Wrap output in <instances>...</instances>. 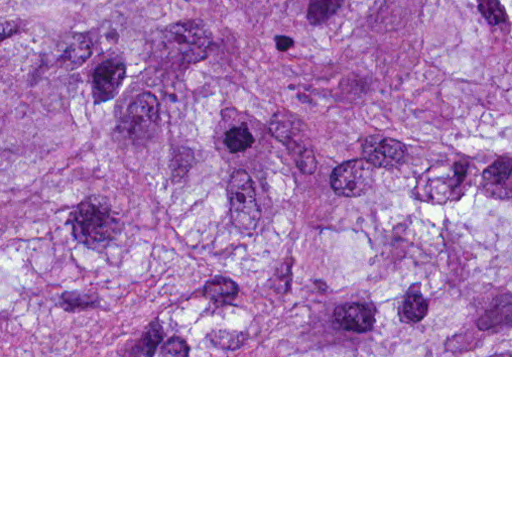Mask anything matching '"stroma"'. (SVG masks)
<instances>
[{
  "label": "stroma",
  "instance_id": "stroma-1",
  "mask_svg": "<svg viewBox=\"0 0 512 512\" xmlns=\"http://www.w3.org/2000/svg\"><path fill=\"white\" fill-rule=\"evenodd\" d=\"M0 357H512V356H0Z\"/></svg>",
  "mask_w": 512,
  "mask_h": 512
}]
</instances>
